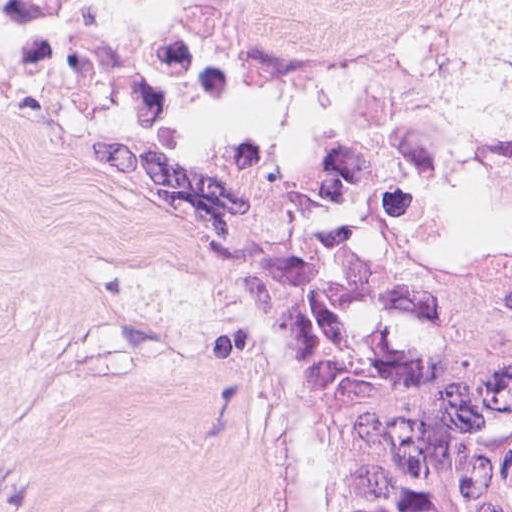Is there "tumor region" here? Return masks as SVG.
<instances>
[{"instance_id": "obj_1", "label": "tumor region", "mask_w": 512, "mask_h": 512, "mask_svg": "<svg viewBox=\"0 0 512 512\" xmlns=\"http://www.w3.org/2000/svg\"><path fill=\"white\" fill-rule=\"evenodd\" d=\"M483 175L512 203V111L483 126ZM457 176L445 99L396 83L290 139L191 94L76 181L93 219L228 306L306 512H512V238L442 208Z\"/></svg>"}]
</instances>
